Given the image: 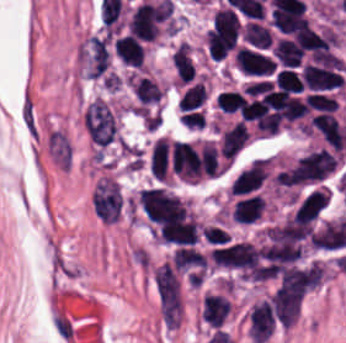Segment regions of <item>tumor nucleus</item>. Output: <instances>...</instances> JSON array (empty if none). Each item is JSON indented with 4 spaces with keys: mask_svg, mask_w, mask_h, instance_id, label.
I'll use <instances>...</instances> for the list:
<instances>
[{
    "mask_svg": "<svg viewBox=\"0 0 346 343\" xmlns=\"http://www.w3.org/2000/svg\"><path fill=\"white\" fill-rule=\"evenodd\" d=\"M208 96L209 92L205 81L197 80L182 89L177 99V106L186 110L201 107L206 102Z\"/></svg>",
    "mask_w": 346,
    "mask_h": 343,
    "instance_id": "2cbd58db",
    "label": "tumor nucleus"
},
{
    "mask_svg": "<svg viewBox=\"0 0 346 343\" xmlns=\"http://www.w3.org/2000/svg\"><path fill=\"white\" fill-rule=\"evenodd\" d=\"M196 73L193 46L180 40L171 49L170 86L180 90L193 82Z\"/></svg>",
    "mask_w": 346,
    "mask_h": 343,
    "instance_id": "2f306a5c",
    "label": "tumor nucleus"
},
{
    "mask_svg": "<svg viewBox=\"0 0 346 343\" xmlns=\"http://www.w3.org/2000/svg\"><path fill=\"white\" fill-rule=\"evenodd\" d=\"M235 306L228 290H211L201 296L200 319L217 328L234 313Z\"/></svg>",
    "mask_w": 346,
    "mask_h": 343,
    "instance_id": "8643909e",
    "label": "tumor nucleus"
},
{
    "mask_svg": "<svg viewBox=\"0 0 346 343\" xmlns=\"http://www.w3.org/2000/svg\"><path fill=\"white\" fill-rule=\"evenodd\" d=\"M240 36L243 42L255 48H269L272 34L267 22L259 20H245L240 26Z\"/></svg>",
    "mask_w": 346,
    "mask_h": 343,
    "instance_id": "5ab6c2c4",
    "label": "tumor nucleus"
}]
</instances>
